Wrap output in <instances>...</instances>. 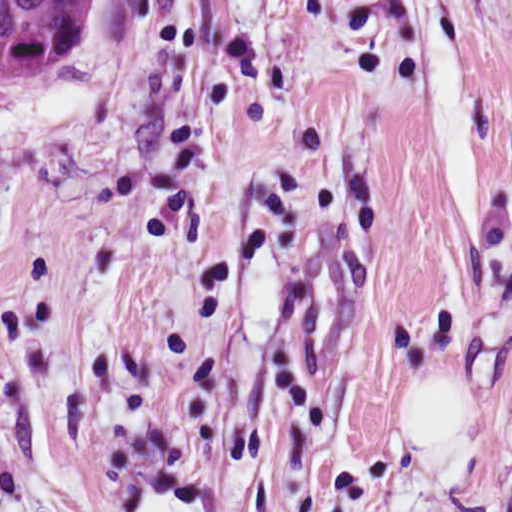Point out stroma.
<instances>
[{
	"label": "stroma",
	"instance_id": "35a3bbf8",
	"mask_svg": "<svg viewBox=\"0 0 512 512\" xmlns=\"http://www.w3.org/2000/svg\"><path fill=\"white\" fill-rule=\"evenodd\" d=\"M512 24V0H96L0 77V252Z\"/></svg>",
	"mask_w": 512,
	"mask_h": 512
}]
</instances>
